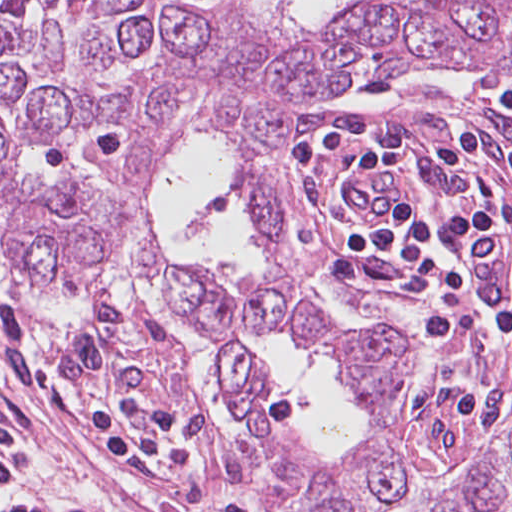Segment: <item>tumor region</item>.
Here are the masks:
<instances>
[{
	"label": "tumor region",
	"instance_id": "tumor-region-1",
	"mask_svg": "<svg viewBox=\"0 0 512 512\" xmlns=\"http://www.w3.org/2000/svg\"><path fill=\"white\" fill-rule=\"evenodd\" d=\"M512 72V0H363L302 26L263 3L0 0V238L29 293L130 277L158 285L214 348L236 397L221 467L269 512H385L408 490L390 328L303 295L283 192V126L302 102L364 75ZM214 132L258 256L245 290L169 259L152 224L160 160ZM239 336L282 339L336 365L372 430L339 462L301 451L291 415ZM444 512H512V421Z\"/></svg>",
	"mask_w": 512,
	"mask_h": 512
}]
</instances>
